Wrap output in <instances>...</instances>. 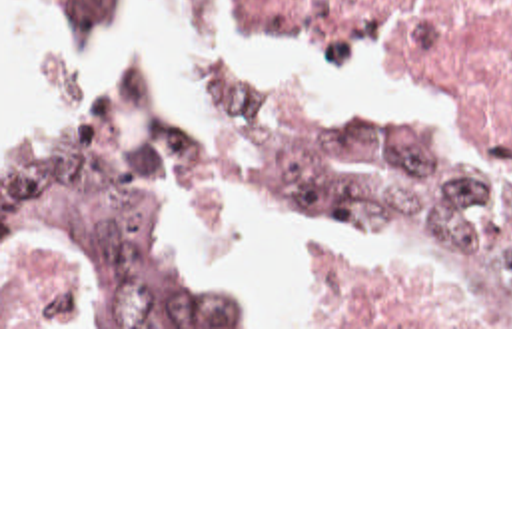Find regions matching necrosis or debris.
Instances as JSON below:
<instances>
[{
  "label": "necrosis or debris",
  "instance_id": "4bbe7bcc",
  "mask_svg": "<svg viewBox=\"0 0 512 512\" xmlns=\"http://www.w3.org/2000/svg\"><path fill=\"white\" fill-rule=\"evenodd\" d=\"M222 0H182L218 18ZM238 16L321 40L389 36L419 73L469 99L477 125L512 145V0H228Z\"/></svg>",
  "mask_w": 512,
  "mask_h": 512
}]
</instances>
